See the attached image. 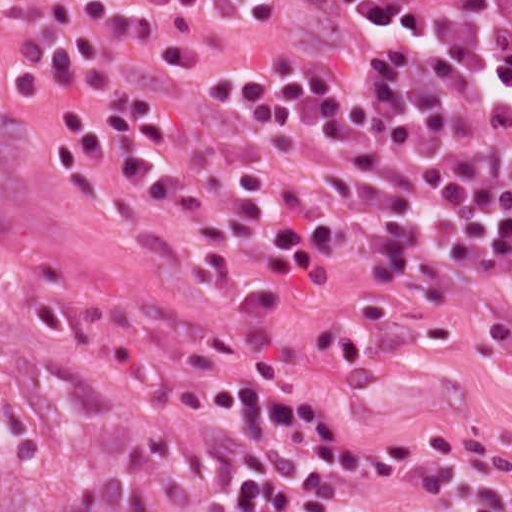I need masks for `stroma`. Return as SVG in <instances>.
Listing matches in <instances>:
<instances>
[{"instance_id":"35a3bbf8","label":"stroma","mask_w":512,"mask_h":512,"mask_svg":"<svg viewBox=\"0 0 512 512\" xmlns=\"http://www.w3.org/2000/svg\"><path fill=\"white\" fill-rule=\"evenodd\" d=\"M33 0H0V58ZM363 259L306 291L227 288L201 259L102 206L51 116L0 87V335L83 434L177 512H222L231 408L257 378L365 444L357 512H414L434 462L472 433H512V357L482 317L362 301ZM457 329L450 340L431 327Z\"/></svg>"}]
</instances>
